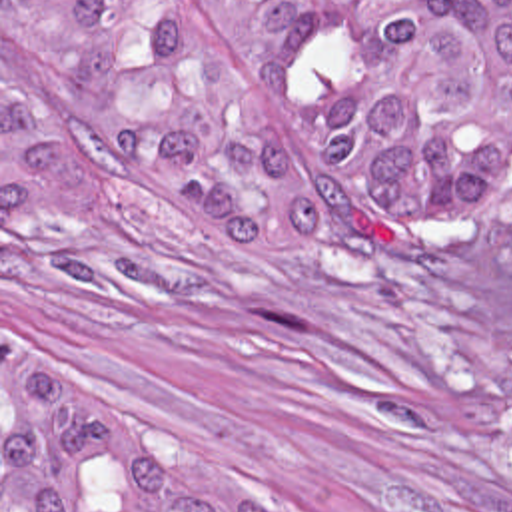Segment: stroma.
I'll return each mask as SVG.
<instances>
[{
    "instance_id": "stroma-1",
    "label": "stroma",
    "mask_w": 512,
    "mask_h": 512,
    "mask_svg": "<svg viewBox=\"0 0 512 512\" xmlns=\"http://www.w3.org/2000/svg\"><path fill=\"white\" fill-rule=\"evenodd\" d=\"M308 212L309 258L280 281L156 228L120 174L90 216L2 226L0 0V512L10 343L268 512H512V218L357 248Z\"/></svg>"
}]
</instances>
